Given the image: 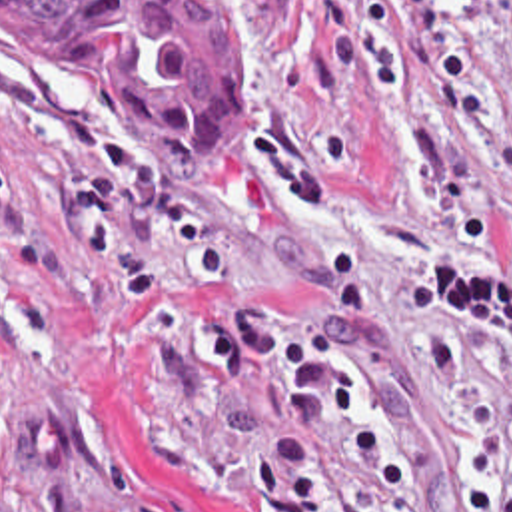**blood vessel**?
Masks as SVG:
<instances>
[{"mask_svg": "<svg viewBox=\"0 0 512 512\" xmlns=\"http://www.w3.org/2000/svg\"><path fill=\"white\" fill-rule=\"evenodd\" d=\"M56 407L36 409L22 423L24 441L34 463L60 461V417Z\"/></svg>", "mask_w": 512, "mask_h": 512, "instance_id": "8fb6f2fc", "label": "blood vessel"}]
</instances>
